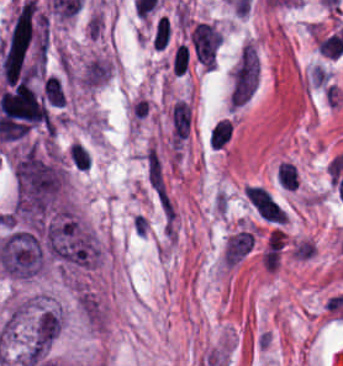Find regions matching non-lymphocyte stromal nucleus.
Wrapping results in <instances>:
<instances>
[{
    "mask_svg": "<svg viewBox=\"0 0 343 366\" xmlns=\"http://www.w3.org/2000/svg\"><path fill=\"white\" fill-rule=\"evenodd\" d=\"M170 139L180 145L188 136L190 126V107L188 103L177 100L170 105L168 112Z\"/></svg>",
    "mask_w": 343,
    "mask_h": 366,
    "instance_id": "1",
    "label": "non-lymphocyte stromal nucleus"
},
{
    "mask_svg": "<svg viewBox=\"0 0 343 366\" xmlns=\"http://www.w3.org/2000/svg\"><path fill=\"white\" fill-rule=\"evenodd\" d=\"M254 240L253 231L240 230L225 241L224 266L233 267L252 248Z\"/></svg>",
    "mask_w": 343,
    "mask_h": 366,
    "instance_id": "2",
    "label": "non-lymphocyte stromal nucleus"
}]
</instances>
